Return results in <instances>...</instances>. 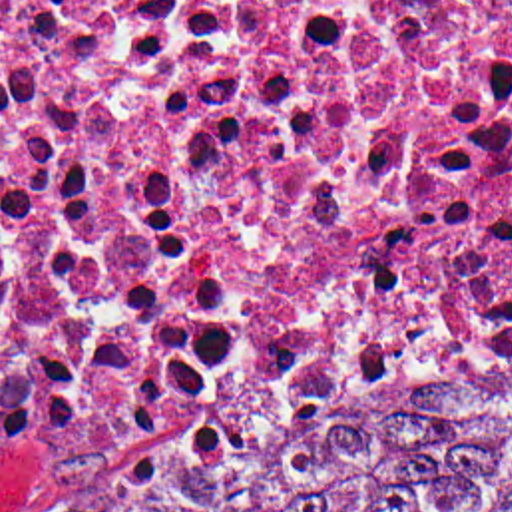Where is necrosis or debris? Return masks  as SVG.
I'll return each instance as SVG.
<instances>
[{"label":"necrosis or debris","mask_w":512,"mask_h":512,"mask_svg":"<svg viewBox=\"0 0 512 512\" xmlns=\"http://www.w3.org/2000/svg\"><path fill=\"white\" fill-rule=\"evenodd\" d=\"M512 362V0H0V476L207 460Z\"/></svg>","instance_id":"obj_1"}]
</instances>
